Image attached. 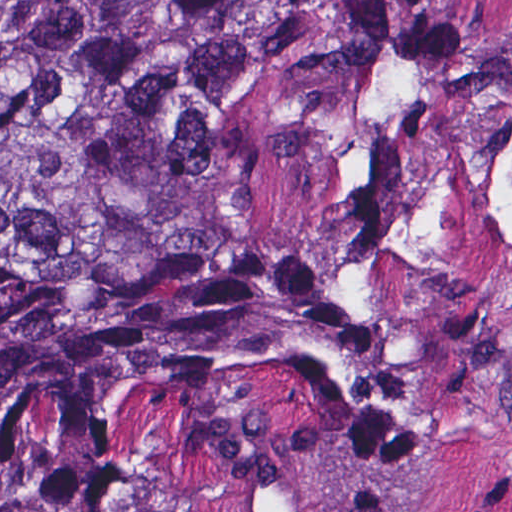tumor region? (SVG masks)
Returning a JSON list of instances; mask_svg holds the SVG:
<instances>
[{"label":"tumor region","mask_w":512,"mask_h":512,"mask_svg":"<svg viewBox=\"0 0 512 512\" xmlns=\"http://www.w3.org/2000/svg\"><path fill=\"white\" fill-rule=\"evenodd\" d=\"M511 358L512 50L401 8L0 0V512L405 465Z\"/></svg>","instance_id":"obj_1"}]
</instances>
